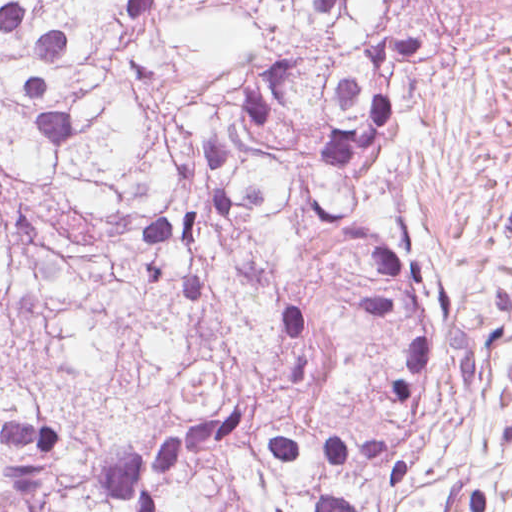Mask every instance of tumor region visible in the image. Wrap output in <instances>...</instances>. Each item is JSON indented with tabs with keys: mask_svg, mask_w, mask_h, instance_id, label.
Masks as SVG:
<instances>
[{
	"mask_svg": "<svg viewBox=\"0 0 512 512\" xmlns=\"http://www.w3.org/2000/svg\"><path fill=\"white\" fill-rule=\"evenodd\" d=\"M512 0H0V512H368L509 276L397 196Z\"/></svg>",
	"mask_w": 512,
	"mask_h": 512,
	"instance_id": "tumor-region-1",
	"label": "tumor region"
}]
</instances>
